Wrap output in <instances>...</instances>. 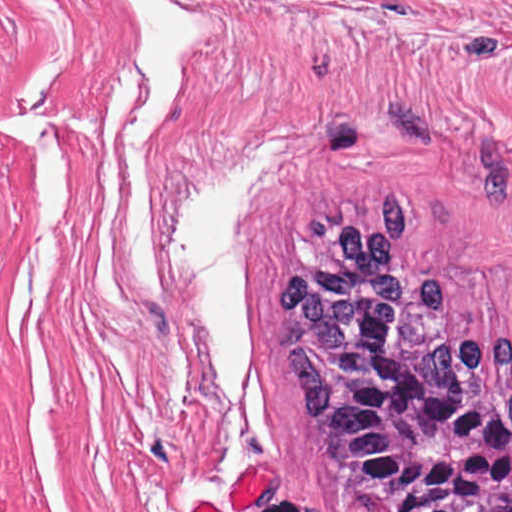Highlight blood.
Instances as JSON below:
<instances>
[{"label":"blood","mask_w":512,"mask_h":512,"mask_svg":"<svg viewBox=\"0 0 512 512\" xmlns=\"http://www.w3.org/2000/svg\"><path fill=\"white\" fill-rule=\"evenodd\" d=\"M273 468L252 466L231 489L233 512H239L266 492L272 484ZM194 512H218L200 502Z\"/></svg>","instance_id":"blood-1"}]
</instances>
